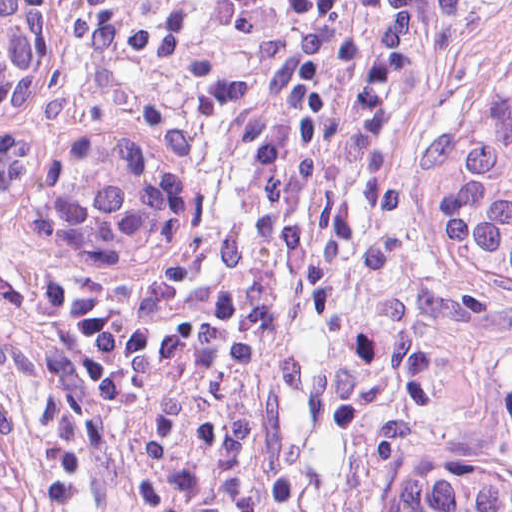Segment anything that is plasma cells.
Listing matches in <instances>:
<instances>
[{
    "instance_id": "obj_1",
    "label": "plasma cells",
    "mask_w": 512,
    "mask_h": 512,
    "mask_svg": "<svg viewBox=\"0 0 512 512\" xmlns=\"http://www.w3.org/2000/svg\"><path fill=\"white\" fill-rule=\"evenodd\" d=\"M87 1L188 177L196 265L125 414L43 512H257L299 197L398 0Z\"/></svg>"
}]
</instances>
